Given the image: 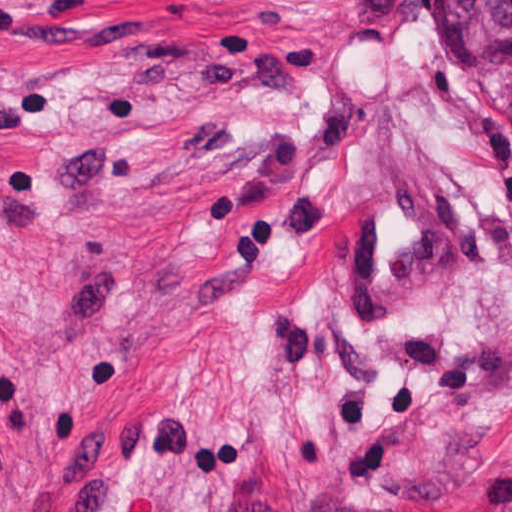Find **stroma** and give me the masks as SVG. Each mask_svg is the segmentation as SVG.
<instances>
[{
  "mask_svg": "<svg viewBox=\"0 0 512 512\" xmlns=\"http://www.w3.org/2000/svg\"><path fill=\"white\" fill-rule=\"evenodd\" d=\"M403 174L439 279L350 328ZM0 512H512V46L439 0H0Z\"/></svg>",
  "mask_w": 512,
  "mask_h": 512,
  "instance_id": "stroma-1",
  "label": "stroma"
}]
</instances>
